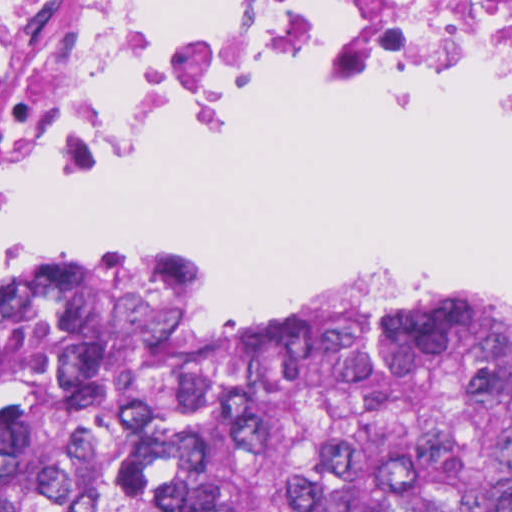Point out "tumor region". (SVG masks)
<instances>
[{
    "instance_id": "e687c5a6",
    "label": "tumor region",
    "mask_w": 512,
    "mask_h": 512,
    "mask_svg": "<svg viewBox=\"0 0 512 512\" xmlns=\"http://www.w3.org/2000/svg\"><path fill=\"white\" fill-rule=\"evenodd\" d=\"M0 512H512V291L0 293Z\"/></svg>"
}]
</instances>
